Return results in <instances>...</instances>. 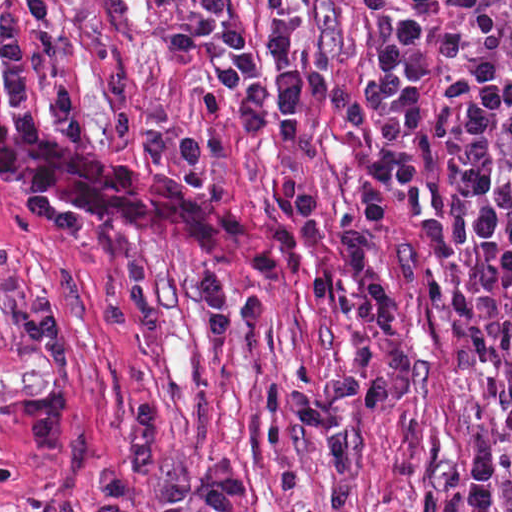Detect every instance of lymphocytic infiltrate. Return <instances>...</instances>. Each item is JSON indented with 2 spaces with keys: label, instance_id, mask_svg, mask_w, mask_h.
I'll return each mask as SVG.
<instances>
[{
  "label": "lymphocytic infiltrate",
  "instance_id": "lymphocytic-infiltrate-1",
  "mask_svg": "<svg viewBox=\"0 0 512 512\" xmlns=\"http://www.w3.org/2000/svg\"><path fill=\"white\" fill-rule=\"evenodd\" d=\"M54 8L55 0H24L0 25L2 81L27 124L36 123L27 101L28 40ZM424 33L422 12H397L354 81L308 61L302 25L290 13L272 19L263 38L256 39L228 0H193L189 17L167 38L176 52L206 61L200 102L208 114L224 115L233 101L240 108L242 134L259 140L273 130L298 141L314 106L322 104L347 122L372 172L386 169L393 187H417L425 177L429 91ZM423 237L442 276L448 344L468 372L493 371L505 412V422L483 430L471 450L465 512H491L504 455L512 452V258L473 246L461 210L449 228L438 219L427 220ZM98 479L101 500L94 512H140L136 494L142 482L157 487L163 512H244L247 504V478L228 459L207 456L186 481L163 465L151 402L131 411L123 426V460L100 468Z\"/></svg>",
  "mask_w": 512,
  "mask_h": 512
}]
</instances>
